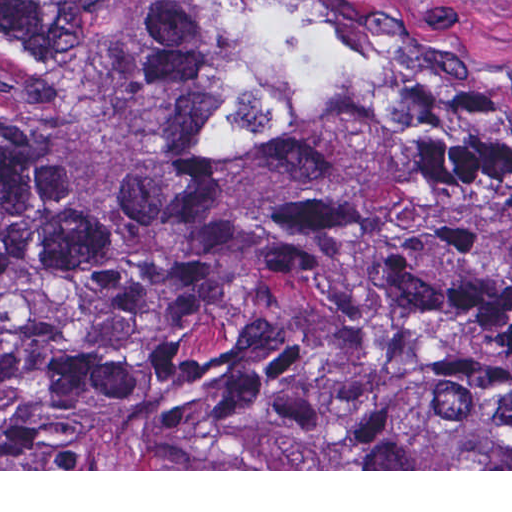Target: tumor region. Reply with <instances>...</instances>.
Returning <instances> with one entry per match:
<instances>
[{"label":"tumor region","mask_w":512,"mask_h":512,"mask_svg":"<svg viewBox=\"0 0 512 512\" xmlns=\"http://www.w3.org/2000/svg\"><path fill=\"white\" fill-rule=\"evenodd\" d=\"M0 469H512V120L244 0H0Z\"/></svg>","instance_id":"obj_1"}]
</instances>
